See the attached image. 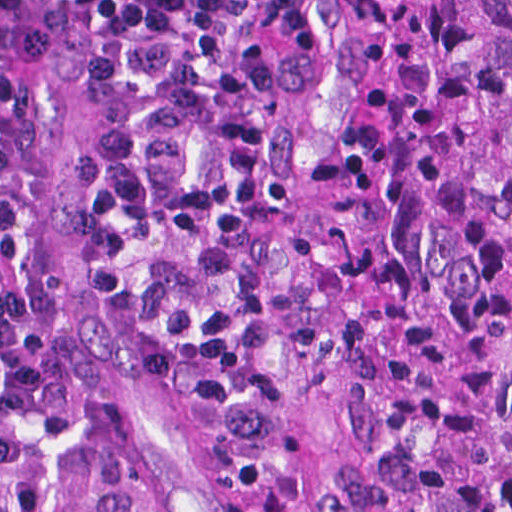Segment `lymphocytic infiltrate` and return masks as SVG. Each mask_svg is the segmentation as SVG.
Here are the masks:
<instances>
[{
	"mask_svg": "<svg viewBox=\"0 0 512 512\" xmlns=\"http://www.w3.org/2000/svg\"><path fill=\"white\" fill-rule=\"evenodd\" d=\"M280 0H0V512H159L120 473L67 354L41 188L62 88L101 294L172 405L268 464L309 434L287 337L304 202L276 170Z\"/></svg>",
	"mask_w": 512,
	"mask_h": 512,
	"instance_id": "obj_1",
	"label": "lymphocytic infiltrate"
}]
</instances>
